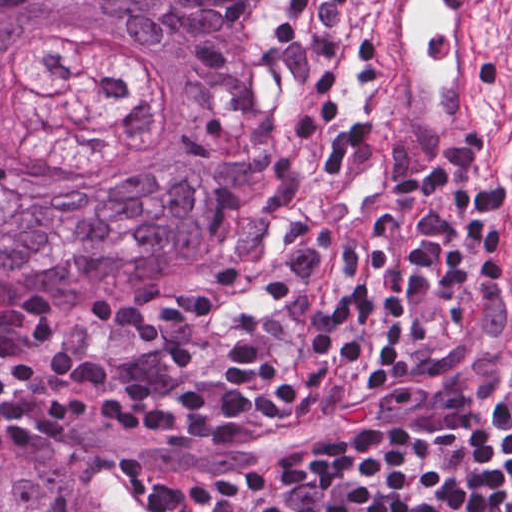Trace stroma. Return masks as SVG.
Masks as SVG:
<instances>
[{
	"label": "stroma",
	"mask_w": 512,
	"mask_h": 512,
	"mask_svg": "<svg viewBox=\"0 0 512 512\" xmlns=\"http://www.w3.org/2000/svg\"><path fill=\"white\" fill-rule=\"evenodd\" d=\"M508 11L509 51L503 82L481 131L500 215L504 261V319L512 287V0ZM281 40L275 9L258 70L260 90L273 131L270 162L247 209L220 235L186 253L125 277L112 291L59 301L37 310H0V335L33 313L48 308H121L191 304L241 289L296 233L309 198L281 82L268 63ZM443 173V172H427ZM1 372V369H0ZM74 429L79 443L68 453L114 484L138 512H154L135 475L133 459L162 470H243L265 458L312 443H168L86 412Z\"/></svg>",
	"instance_id": "obj_1"
}]
</instances>
